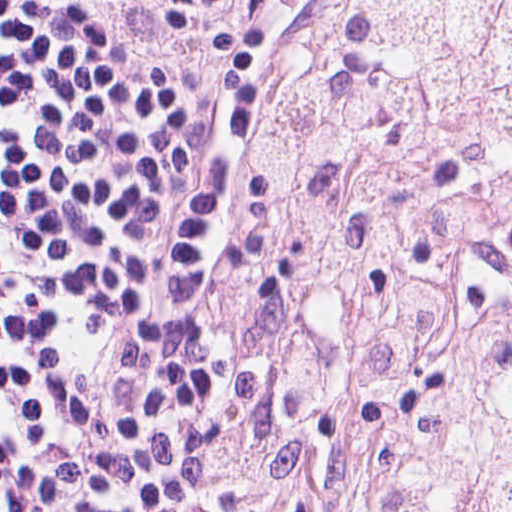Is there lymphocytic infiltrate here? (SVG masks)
Returning a JSON list of instances; mask_svg holds the SVG:
<instances>
[{
	"mask_svg": "<svg viewBox=\"0 0 512 512\" xmlns=\"http://www.w3.org/2000/svg\"><path fill=\"white\" fill-rule=\"evenodd\" d=\"M228 199L216 96H163L64 0H0V512H220L199 276Z\"/></svg>",
	"mask_w": 512,
	"mask_h": 512,
	"instance_id": "1",
	"label": "lymphocytic infiltrate"
}]
</instances>
